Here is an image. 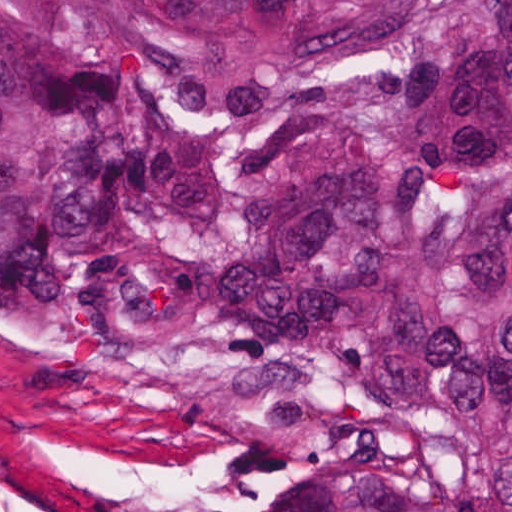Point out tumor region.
Masks as SVG:
<instances>
[{"label": "tumor region", "instance_id": "e687c5a6", "mask_svg": "<svg viewBox=\"0 0 512 512\" xmlns=\"http://www.w3.org/2000/svg\"><path fill=\"white\" fill-rule=\"evenodd\" d=\"M0 323L224 512H512V0H0Z\"/></svg>", "mask_w": 512, "mask_h": 512}]
</instances>
